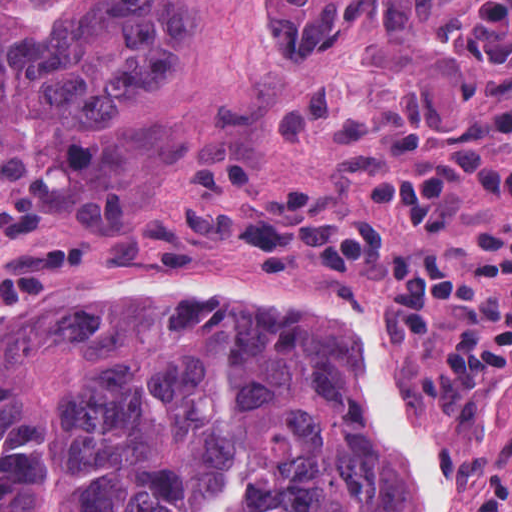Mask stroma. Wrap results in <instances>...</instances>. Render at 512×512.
<instances>
[{
  "instance_id": "obj_1",
  "label": "stroma",
  "mask_w": 512,
  "mask_h": 512,
  "mask_svg": "<svg viewBox=\"0 0 512 512\" xmlns=\"http://www.w3.org/2000/svg\"><path fill=\"white\" fill-rule=\"evenodd\" d=\"M261 0H205L198 32L178 62L135 95L98 110L103 128L158 131L176 126L204 145L148 191L111 195L62 225L0 237V303L157 275L196 279L156 295L206 296L279 321L330 322L331 329L215 314L104 303L131 314L167 315L230 339L312 341L345 331L366 354L387 422L430 468L437 512H512V385L462 388L442 363L402 354L387 342L379 288L337 270L304 268L262 278L240 268L228 248L221 178L235 167L256 190L311 191L325 216L369 220L398 242L444 250L458 264L475 256L486 221H509L483 208L470 184L449 241L415 235L401 218L369 214L365 193L336 170V138L280 133L252 112L258 83L316 79L336 95L386 87L414 67L435 77L456 104L512 103V0H457L447 16L398 30L371 0L350 44L321 56H283L261 28ZM92 261V262H91ZM91 304H54L0 313V341L32 311L67 312Z\"/></svg>"
}]
</instances>
